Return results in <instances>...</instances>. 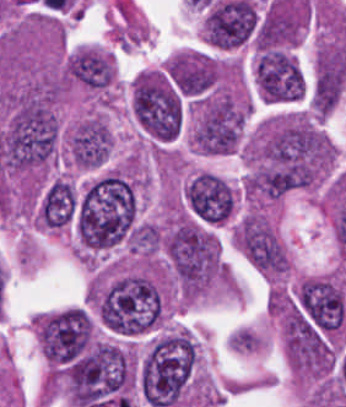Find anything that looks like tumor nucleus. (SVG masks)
Wrapping results in <instances>:
<instances>
[{"label":"tumor nucleus","mask_w":346,"mask_h":407,"mask_svg":"<svg viewBox=\"0 0 346 407\" xmlns=\"http://www.w3.org/2000/svg\"><path fill=\"white\" fill-rule=\"evenodd\" d=\"M136 213V193L128 180L106 171L81 190L73 229L77 253L111 248L126 240Z\"/></svg>","instance_id":"2f306a5c"},{"label":"tumor nucleus","mask_w":346,"mask_h":407,"mask_svg":"<svg viewBox=\"0 0 346 407\" xmlns=\"http://www.w3.org/2000/svg\"><path fill=\"white\" fill-rule=\"evenodd\" d=\"M197 367V347L188 331L170 329L146 352L138 370L142 396L149 407H170L186 400Z\"/></svg>","instance_id":"8643909e"},{"label":"tumor nucleus","mask_w":346,"mask_h":407,"mask_svg":"<svg viewBox=\"0 0 346 407\" xmlns=\"http://www.w3.org/2000/svg\"><path fill=\"white\" fill-rule=\"evenodd\" d=\"M247 106L233 91H219L198 101L190 138L196 149L212 154L239 145Z\"/></svg>","instance_id":"5ab6c2c4"},{"label":"tumor nucleus","mask_w":346,"mask_h":407,"mask_svg":"<svg viewBox=\"0 0 346 407\" xmlns=\"http://www.w3.org/2000/svg\"><path fill=\"white\" fill-rule=\"evenodd\" d=\"M256 86L266 101H292L301 97L304 81L289 52L280 47H261L254 63Z\"/></svg>","instance_id":"2cbd58db"},{"label":"tumor nucleus","mask_w":346,"mask_h":407,"mask_svg":"<svg viewBox=\"0 0 346 407\" xmlns=\"http://www.w3.org/2000/svg\"><path fill=\"white\" fill-rule=\"evenodd\" d=\"M185 199L191 213L208 225H223L235 213V188L217 173H197L185 191Z\"/></svg>","instance_id":"3d1891a8"},{"label":"tumor nucleus","mask_w":346,"mask_h":407,"mask_svg":"<svg viewBox=\"0 0 346 407\" xmlns=\"http://www.w3.org/2000/svg\"><path fill=\"white\" fill-rule=\"evenodd\" d=\"M164 74L182 95L198 97L220 80V69L210 54L181 49L163 66Z\"/></svg>","instance_id":"2083b535"},{"label":"tumor nucleus","mask_w":346,"mask_h":407,"mask_svg":"<svg viewBox=\"0 0 346 407\" xmlns=\"http://www.w3.org/2000/svg\"><path fill=\"white\" fill-rule=\"evenodd\" d=\"M112 147V130L101 116L82 119L66 140L68 161L79 168H96L105 163Z\"/></svg>","instance_id":"8087334f"},{"label":"tumor nucleus","mask_w":346,"mask_h":407,"mask_svg":"<svg viewBox=\"0 0 346 407\" xmlns=\"http://www.w3.org/2000/svg\"><path fill=\"white\" fill-rule=\"evenodd\" d=\"M116 75V64L109 52L87 46L72 53L65 63V76L92 91H107Z\"/></svg>","instance_id":"c2bd9aea"},{"label":"tumor nucleus","mask_w":346,"mask_h":407,"mask_svg":"<svg viewBox=\"0 0 346 407\" xmlns=\"http://www.w3.org/2000/svg\"><path fill=\"white\" fill-rule=\"evenodd\" d=\"M346 82L343 65H318L310 89V107L322 116L332 111Z\"/></svg>","instance_id":"feef74b5"},{"label":"tumor nucleus","mask_w":346,"mask_h":407,"mask_svg":"<svg viewBox=\"0 0 346 407\" xmlns=\"http://www.w3.org/2000/svg\"><path fill=\"white\" fill-rule=\"evenodd\" d=\"M315 65L346 75V45L343 39L322 41L315 53Z\"/></svg>","instance_id":"3e47fb67"},{"label":"tumor nucleus","mask_w":346,"mask_h":407,"mask_svg":"<svg viewBox=\"0 0 346 407\" xmlns=\"http://www.w3.org/2000/svg\"><path fill=\"white\" fill-rule=\"evenodd\" d=\"M160 244V231L154 223H141L130 235L132 253L154 256L158 253Z\"/></svg>","instance_id":"f7901128"}]
</instances>
